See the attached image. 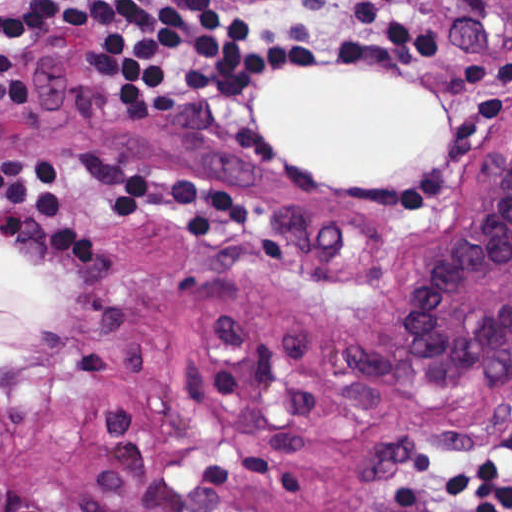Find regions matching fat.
I'll list each match as a JSON object with an SVG mask.
<instances>
[{"label": "fat", "mask_w": 512, "mask_h": 512, "mask_svg": "<svg viewBox=\"0 0 512 512\" xmlns=\"http://www.w3.org/2000/svg\"><path fill=\"white\" fill-rule=\"evenodd\" d=\"M339 71L273 79L257 104L256 134L325 184L400 182L447 144V105L431 84ZM1 243V382L19 376L60 309V289L29 256Z\"/></svg>", "instance_id": "fat-1"}]
</instances>
